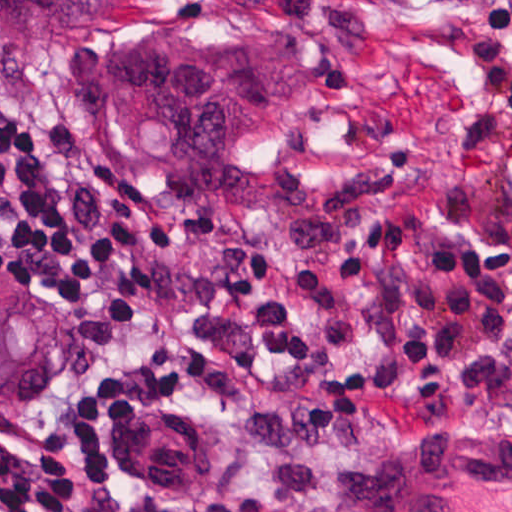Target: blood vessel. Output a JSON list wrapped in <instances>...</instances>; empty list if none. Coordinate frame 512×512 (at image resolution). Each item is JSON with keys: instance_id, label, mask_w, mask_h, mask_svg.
Here are the masks:
<instances>
[{"instance_id": "1", "label": "blood vessel", "mask_w": 512, "mask_h": 512, "mask_svg": "<svg viewBox=\"0 0 512 512\" xmlns=\"http://www.w3.org/2000/svg\"><path fill=\"white\" fill-rule=\"evenodd\" d=\"M362 512H512V431L390 462L373 476Z\"/></svg>"}]
</instances>
